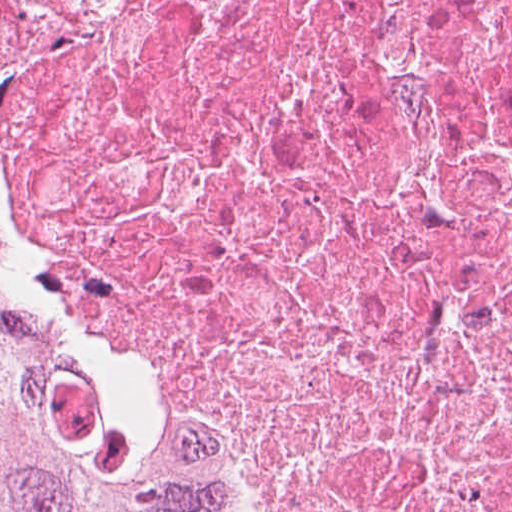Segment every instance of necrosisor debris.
<instances>
[{
    "instance_id": "necrosis-or-debris-1",
    "label": "necrosis or debris",
    "mask_w": 512,
    "mask_h": 512,
    "mask_svg": "<svg viewBox=\"0 0 512 512\" xmlns=\"http://www.w3.org/2000/svg\"><path fill=\"white\" fill-rule=\"evenodd\" d=\"M0 199L272 512H512V0H0Z\"/></svg>"
}]
</instances>
